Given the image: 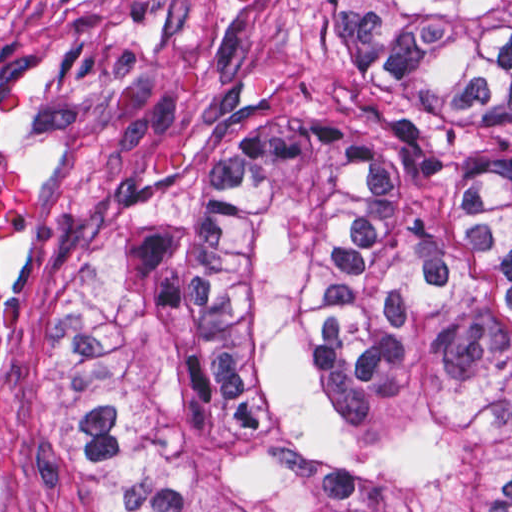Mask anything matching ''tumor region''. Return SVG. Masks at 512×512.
I'll return each instance as SVG.
<instances>
[{"label":"tumor region","instance_id":"tumor-region-1","mask_svg":"<svg viewBox=\"0 0 512 512\" xmlns=\"http://www.w3.org/2000/svg\"><path fill=\"white\" fill-rule=\"evenodd\" d=\"M60 425L107 512H512V0H330L171 313L67 322Z\"/></svg>","mask_w":512,"mask_h":512}]
</instances>
